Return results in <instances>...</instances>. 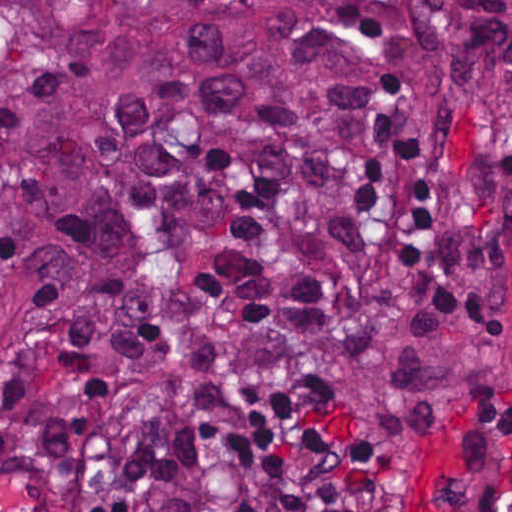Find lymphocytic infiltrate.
I'll return each mask as SVG.
<instances>
[{"mask_svg": "<svg viewBox=\"0 0 512 512\" xmlns=\"http://www.w3.org/2000/svg\"><path fill=\"white\" fill-rule=\"evenodd\" d=\"M384 89L393 97L387 106L376 110V117H390L388 106L397 100L399 95L408 90V85L396 75L388 74L381 78ZM494 210L512 217V185H503L494 189Z\"/></svg>", "mask_w": 512, "mask_h": 512, "instance_id": "obj_1", "label": "lymphocytic infiltrate"}]
</instances>
